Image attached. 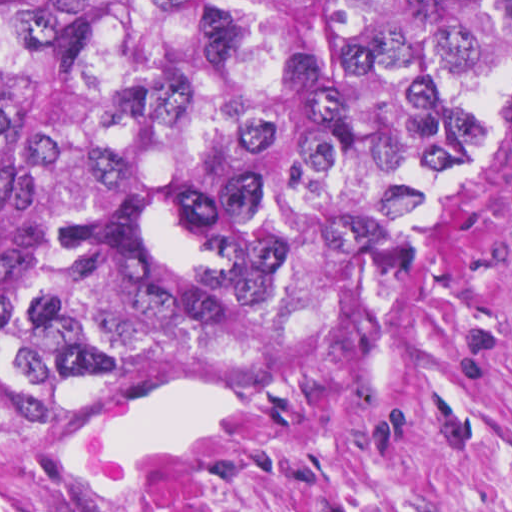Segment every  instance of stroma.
I'll use <instances>...</instances> for the list:
<instances>
[{
    "instance_id": "obj_1",
    "label": "stroma",
    "mask_w": 512,
    "mask_h": 512,
    "mask_svg": "<svg viewBox=\"0 0 512 512\" xmlns=\"http://www.w3.org/2000/svg\"><path fill=\"white\" fill-rule=\"evenodd\" d=\"M447 1L482 35L496 125L384 284L333 311L178 335L147 359L0 416V512H60L38 436L161 377L255 381L240 452L176 512H512V0Z\"/></svg>"
}]
</instances>
